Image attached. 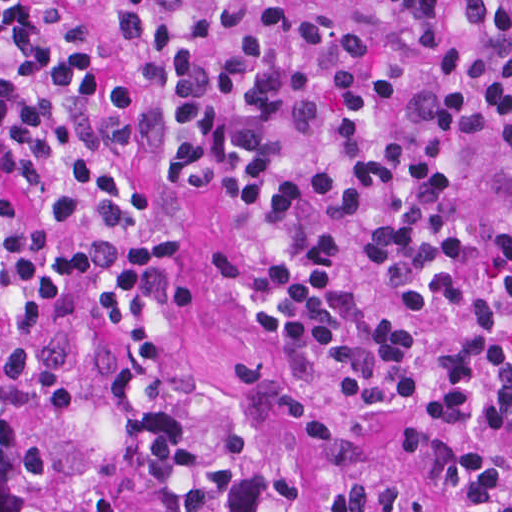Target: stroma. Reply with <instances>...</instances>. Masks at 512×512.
Listing matches in <instances>:
<instances>
[{
	"instance_id": "35a3bbf8",
	"label": "stroma",
	"mask_w": 512,
	"mask_h": 512,
	"mask_svg": "<svg viewBox=\"0 0 512 512\" xmlns=\"http://www.w3.org/2000/svg\"><path fill=\"white\" fill-rule=\"evenodd\" d=\"M131 171L139 187L166 210L160 229L181 237L185 246L170 280L186 292V306L169 325L170 376H197L224 385L252 367L276 379L264 393L260 414L276 446L291 461L298 490L294 512H337L334 493L347 481H376L417 492L422 472L349 463L303 440L283 401H304L345 437L392 451L411 428L415 406L392 395L363 400L341 381L310 376L282 359L237 308L219 260V248L236 253V231L219 198L207 189L176 183L150 156H135Z\"/></svg>"
}]
</instances>
